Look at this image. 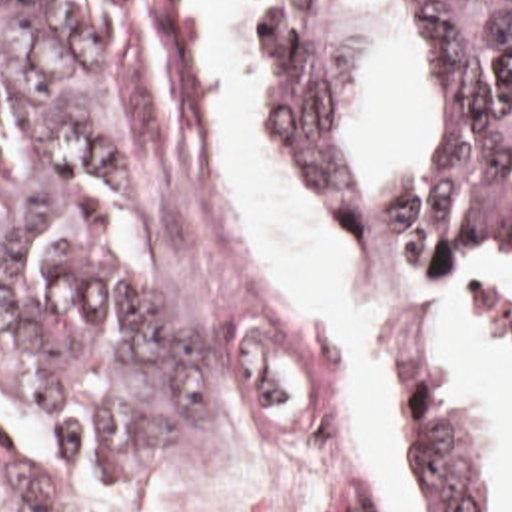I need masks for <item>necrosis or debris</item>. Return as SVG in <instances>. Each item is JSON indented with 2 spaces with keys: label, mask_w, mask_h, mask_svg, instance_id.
Here are the masks:
<instances>
[{
  "label": "necrosis or debris",
  "mask_w": 512,
  "mask_h": 512,
  "mask_svg": "<svg viewBox=\"0 0 512 512\" xmlns=\"http://www.w3.org/2000/svg\"><path fill=\"white\" fill-rule=\"evenodd\" d=\"M0 512H63L49 503L19 467L0 431Z\"/></svg>",
  "instance_id": "1"
}]
</instances>
